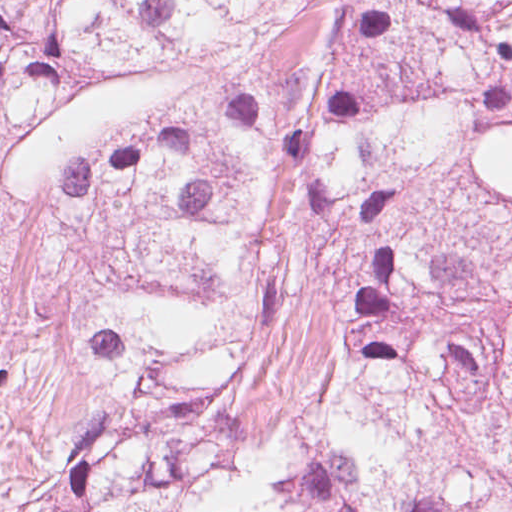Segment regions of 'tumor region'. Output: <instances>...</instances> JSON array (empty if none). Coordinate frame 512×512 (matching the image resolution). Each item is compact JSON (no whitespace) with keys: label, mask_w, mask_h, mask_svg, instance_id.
<instances>
[{"label":"tumor region","mask_w":512,"mask_h":512,"mask_svg":"<svg viewBox=\"0 0 512 512\" xmlns=\"http://www.w3.org/2000/svg\"><path fill=\"white\" fill-rule=\"evenodd\" d=\"M63 194L106 396L34 512H512V273L320 211L319 358L245 444L219 419L270 194L126 148Z\"/></svg>","instance_id":"tumor-region-1"}]
</instances>
